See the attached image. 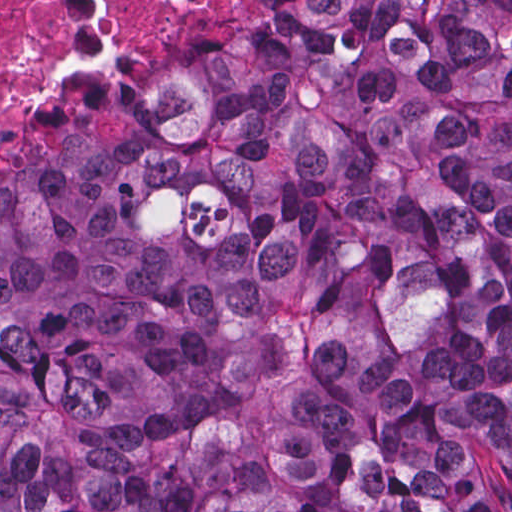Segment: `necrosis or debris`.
<instances>
[{
    "mask_svg": "<svg viewBox=\"0 0 512 512\" xmlns=\"http://www.w3.org/2000/svg\"><path fill=\"white\" fill-rule=\"evenodd\" d=\"M248 1L0 0V138L61 60L97 44L155 41L192 13H233Z\"/></svg>",
    "mask_w": 512,
    "mask_h": 512,
    "instance_id": "obj_1",
    "label": "necrosis or debris"
}]
</instances>
